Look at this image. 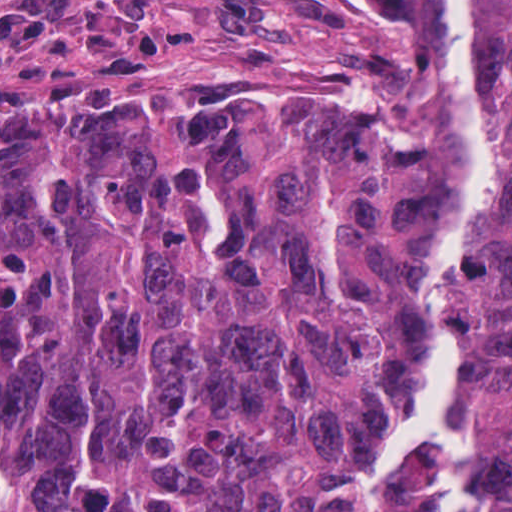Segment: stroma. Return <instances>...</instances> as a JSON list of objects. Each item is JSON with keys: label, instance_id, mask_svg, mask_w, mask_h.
Here are the masks:
<instances>
[{"label": "stroma", "instance_id": "1", "mask_svg": "<svg viewBox=\"0 0 512 512\" xmlns=\"http://www.w3.org/2000/svg\"><path fill=\"white\" fill-rule=\"evenodd\" d=\"M304 33L269 0H0V97Z\"/></svg>", "mask_w": 512, "mask_h": 512}]
</instances>
